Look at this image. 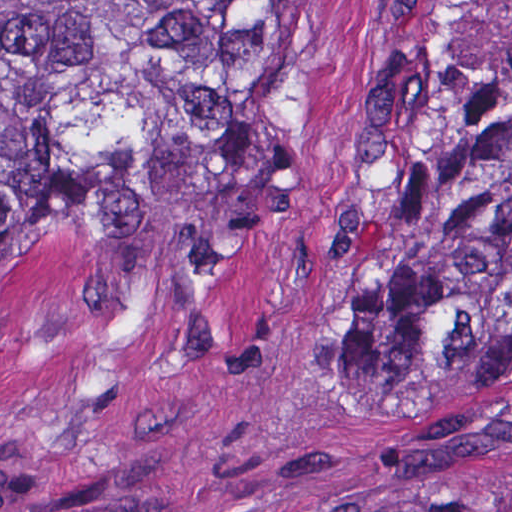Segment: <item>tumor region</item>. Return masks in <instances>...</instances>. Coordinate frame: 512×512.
Returning <instances> with one entry per match:
<instances>
[{"label": "tumor region", "instance_id": "1", "mask_svg": "<svg viewBox=\"0 0 512 512\" xmlns=\"http://www.w3.org/2000/svg\"><path fill=\"white\" fill-rule=\"evenodd\" d=\"M289 0H0V307L16 215L158 290L263 272L285 209ZM381 393L512 379V54L470 81L349 299Z\"/></svg>", "mask_w": 512, "mask_h": 512}]
</instances>
